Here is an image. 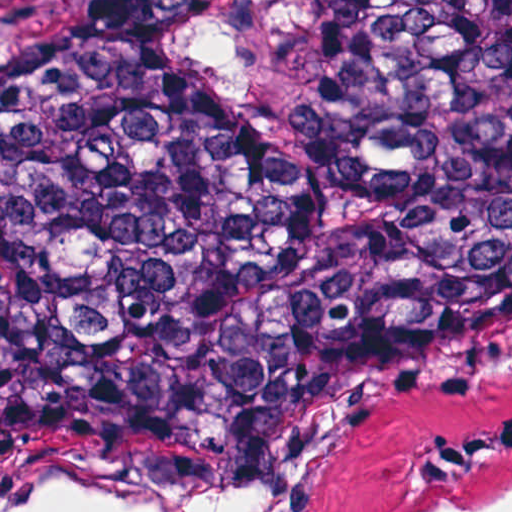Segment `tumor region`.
I'll use <instances>...</instances> for the list:
<instances>
[{
    "label": "tumor region",
    "mask_w": 512,
    "mask_h": 512,
    "mask_svg": "<svg viewBox=\"0 0 512 512\" xmlns=\"http://www.w3.org/2000/svg\"><path fill=\"white\" fill-rule=\"evenodd\" d=\"M210 0H0V431L512 401V0H312L264 136Z\"/></svg>",
    "instance_id": "tumor-region-1"
}]
</instances>
